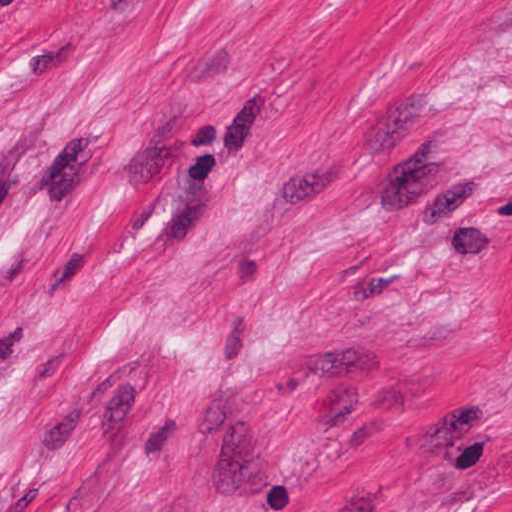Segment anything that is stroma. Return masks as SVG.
<instances>
[{
	"label": "stroma",
	"instance_id": "obj_1",
	"mask_svg": "<svg viewBox=\"0 0 512 512\" xmlns=\"http://www.w3.org/2000/svg\"><path fill=\"white\" fill-rule=\"evenodd\" d=\"M0 512H512V0H0Z\"/></svg>",
	"mask_w": 512,
	"mask_h": 512
}]
</instances>
